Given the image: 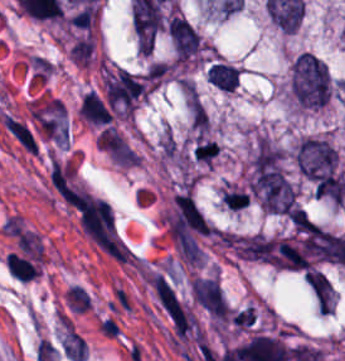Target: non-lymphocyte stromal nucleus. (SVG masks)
I'll return each instance as SVG.
<instances>
[{
    "label": "non-lymphocyte stromal nucleus",
    "instance_id": "dd21d789",
    "mask_svg": "<svg viewBox=\"0 0 345 361\" xmlns=\"http://www.w3.org/2000/svg\"><path fill=\"white\" fill-rule=\"evenodd\" d=\"M152 292L176 343L199 336V322L194 310L167 278H153Z\"/></svg>",
    "mask_w": 345,
    "mask_h": 361
},
{
    "label": "non-lymphocyte stromal nucleus",
    "instance_id": "a72fc3eb",
    "mask_svg": "<svg viewBox=\"0 0 345 361\" xmlns=\"http://www.w3.org/2000/svg\"><path fill=\"white\" fill-rule=\"evenodd\" d=\"M46 179L60 201L74 211L79 212L91 195L72 157H52Z\"/></svg>",
    "mask_w": 345,
    "mask_h": 361
},
{
    "label": "non-lymphocyte stromal nucleus",
    "instance_id": "3746e769",
    "mask_svg": "<svg viewBox=\"0 0 345 361\" xmlns=\"http://www.w3.org/2000/svg\"><path fill=\"white\" fill-rule=\"evenodd\" d=\"M80 222L100 247L112 250L116 245L114 215L108 201L84 196L79 206Z\"/></svg>",
    "mask_w": 345,
    "mask_h": 361
},
{
    "label": "non-lymphocyte stromal nucleus",
    "instance_id": "fc2b8d12",
    "mask_svg": "<svg viewBox=\"0 0 345 361\" xmlns=\"http://www.w3.org/2000/svg\"><path fill=\"white\" fill-rule=\"evenodd\" d=\"M2 125L19 148L28 154H36L39 151V136L28 120L3 111L1 115Z\"/></svg>",
    "mask_w": 345,
    "mask_h": 361
}]
</instances>
